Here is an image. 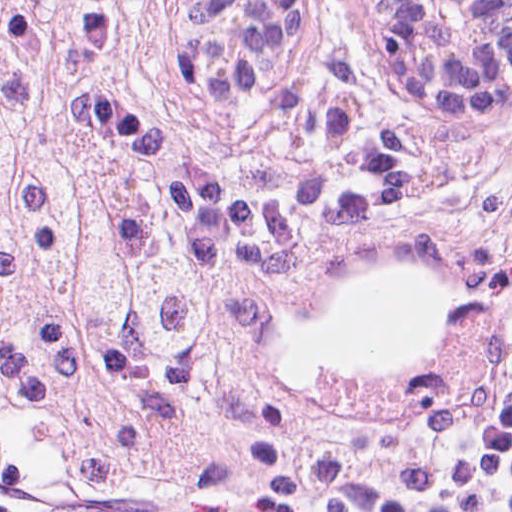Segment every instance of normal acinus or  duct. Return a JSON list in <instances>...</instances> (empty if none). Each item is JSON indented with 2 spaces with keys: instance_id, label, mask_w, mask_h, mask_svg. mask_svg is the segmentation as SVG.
<instances>
[{
  "instance_id": "1",
  "label": "normal acinus or duct",
  "mask_w": 512,
  "mask_h": 512,
  "mask_svg": "<svg viewBox=\"0 0 512 512\" xmlns=\"http://www.w3.org/2000/svg\"><path fill=\"white\" fill-rule=\"evenodd\" d=\"M176 67L192 105L245 106L291 0H170ZM358 34L423 114L497 121L512 91V0H350Z\"/></svg>"
}]
</instances>
